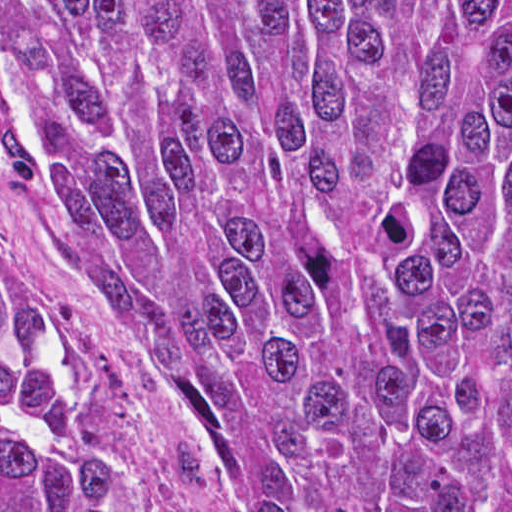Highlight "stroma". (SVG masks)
I'll return each mask as SVG.
<instances>
[{"label": "stroma", "instance_id": "obj_1", "mask_svg": "<svg viewBox=\"0 0 512 512\" xmlns=\"http://www.w3.org/2000/svg\"><path fill=\"white\" fill-rule=\"evenodd\" d=\"M0 243L92 375L170 512H252L193 395L116 298L1 73Z\"/></svg>", "mask_w": 512, "mask_h": 512}]
</instances>
